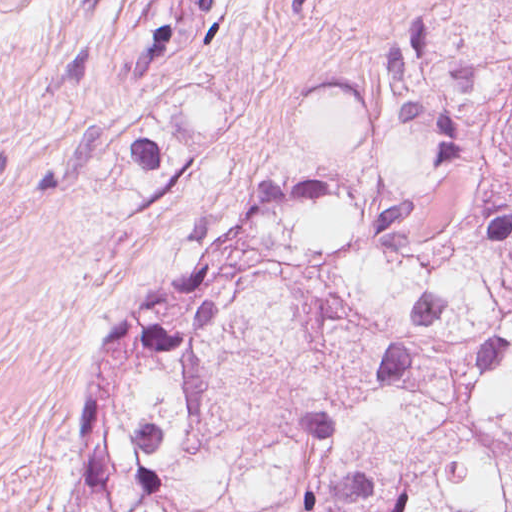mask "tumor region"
I'll return each instance as SVG.
<instances>
[{
    "label": "tumor region",
    "instance_id": "tumor-region-1",
    "mask_svg": "<svg viewBox=\"0 0 512 512\" xmlns=\"http://www.w3.org/2000/svg\"><path fill=\"white\" fill-rule=\"evenodd\" d=\"M83 512H512V28L396 41L355 150L115 337Z\"/></svg>",
    "mask_w": 512,
    "mask_h": 512
}]
</instances>
